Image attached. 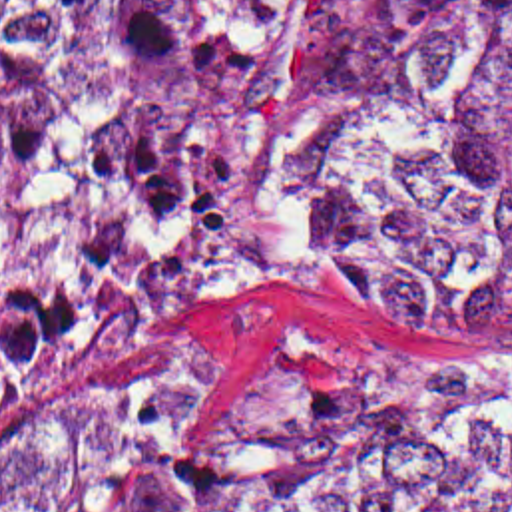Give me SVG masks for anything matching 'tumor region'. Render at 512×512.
Listing matches in <instances>:
<instances>
[{
    "mask_svg": "<svg viewBox=\"0 0 512 512\" xmlns=\"http://www.w3.org/2000/svg\"><path fill=\"white\" fill-rule=\"evenodd\" d=\"M293 7L0 0V424L225 280V113ZM363 63L442 185L319 264L512 346V0H363ZM422 192L361 97L321 99L259 153L257 234L315 252ZM185 394L187 354L143 364L0 465V512H512V352L426 392H261L215 465L181 461Z\"/></svg>",
    "mask_w": 512,
    "mask_h": 512,
    "instance_id": "e687c5a6",
    "label": "tumor region"
}]
</instances>
